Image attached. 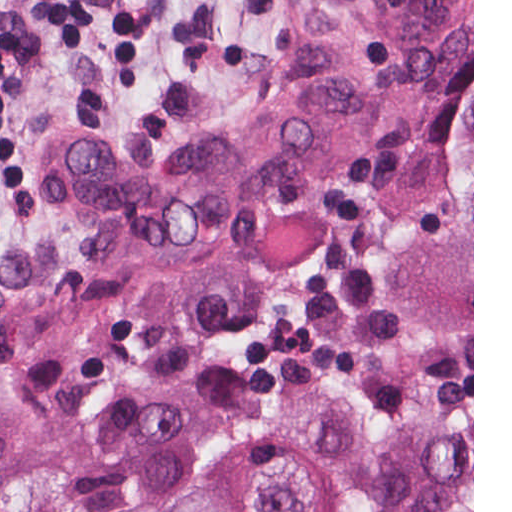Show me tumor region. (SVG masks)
<instances>
[{
    "label": "tumor region",
    "instance_id": "tumor-region-1",
    "mask_svg": "<svg viewBox=\"0 0 512 512\" xmlns=\"http://www.w3.org/2000/svg\"><path fill=\"white\" fill-rule=\"evenodd\" d=\"M472 108V0H306L290 79L246 111L134 143L52 140L41 183L81 266L0 244V356L190 369L371 238L389 178ZM149 512H472V422L385 428L296 378L260 450Z\"/></svg>",
    "mask_w": 512,
    "mask_h": 512
}]
</instances>
